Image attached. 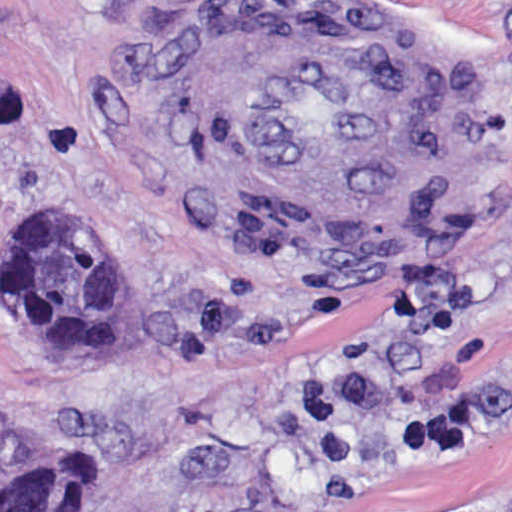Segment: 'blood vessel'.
<instances>
[{
  "instance_id": "8fb6f2fc",
  "label": "blood vessel",
  "mask_w": 512,
  "mask_h": 512,
  "mask_svg": "<svg viewBox=\"0 0 512 512\" xmlns=\"http://www.w3.org/2000/svg\"><path fill=\"white\" fill-rule=\"evenodd\" d=\"M209 87L243 168L297 229H371L402 195L403 96L363 31L238 9L213 35Z\"/></svg>"
}]
</instances>
